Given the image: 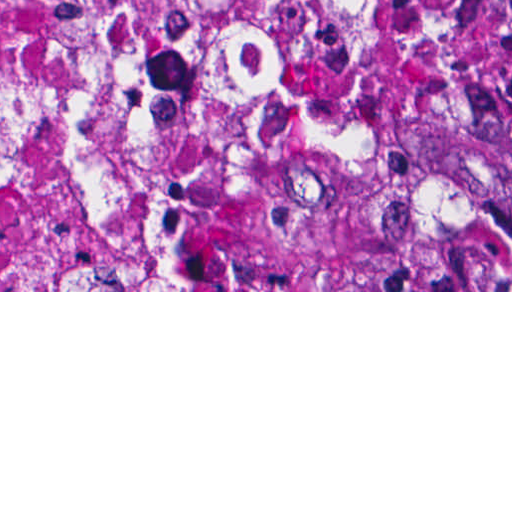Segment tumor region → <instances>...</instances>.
Here are the masks:
<instances>
[{
    "instance_id": "tumor-region-1",
    "label": "tumor region",
    "mask_w": 512,
    "mask_h": 512,
    "mask_svg": "<svg viewBox=\"0 0 512 512\" xmlns=\"http://www.w3.org/2000/svg\"><path fill=\"white\" fill-rule=\"evenodd\" d=\"M511 17L512 0H469V68L478 113L489 101L498 26ZM492 231L512 254V146L499 179Z\"/></svg>"
}]
</instances>
